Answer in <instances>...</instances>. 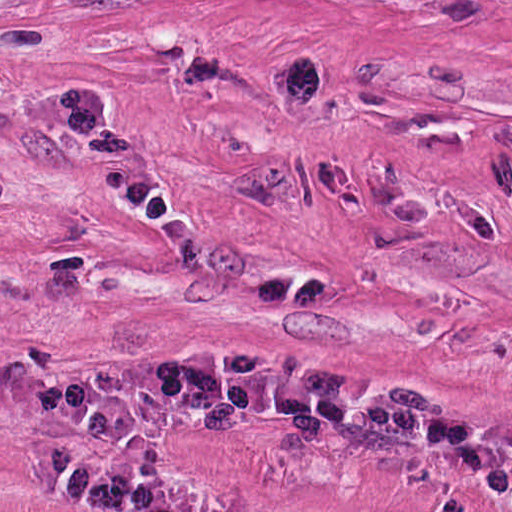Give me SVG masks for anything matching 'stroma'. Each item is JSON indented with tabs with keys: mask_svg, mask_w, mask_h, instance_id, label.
Here are the masks:
<instances>
[{
	"mask_svg": "<svg viewBox=\"0 0 512 512\" xmlns=\"http://www.w3.org/2000/svg\"><path fill=\"white\" fill-rule=\"evenodd\" d=\"M0 464L512 512V0H0Z\"/></svg>",
	"mask_w": 512,
	"mask_h": 512,
	"instance_id": "stroma-1",
	"label": "stroma"
}]
</instances>
